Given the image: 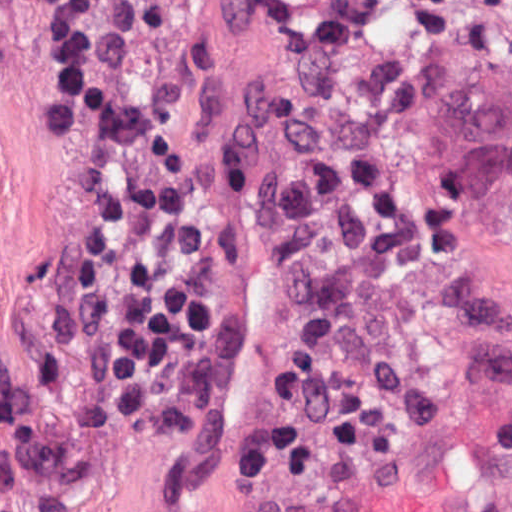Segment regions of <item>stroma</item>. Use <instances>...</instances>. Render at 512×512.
<instances>
[{
	"instance_id": "1",
	"label": "stroma",
	"mask_w": 512,
	"mask_h": 512,
	"mask_svg": "<svg viewBox=\"0 0 512 512\" xmlns=\"http://www.w3.org/2000/svg\"><path fill=\"white\" fill-rule=\"evenodd\" d=\"M58 1L0 0V512H251L292 485L250 487L236 448L314 330L318 303L293 257L204 156L239 2L211 0L190 14L192 69L168 94L111 92L85 63L82 97L64 124L63 73L46 43ZM108 115H128L241 282L237 379L188 444L103 401L106 370L79 283L91 198L79 139ZM508 420L512 382L472 395L367 463Z\"/></svg>"
}]
</instances>
